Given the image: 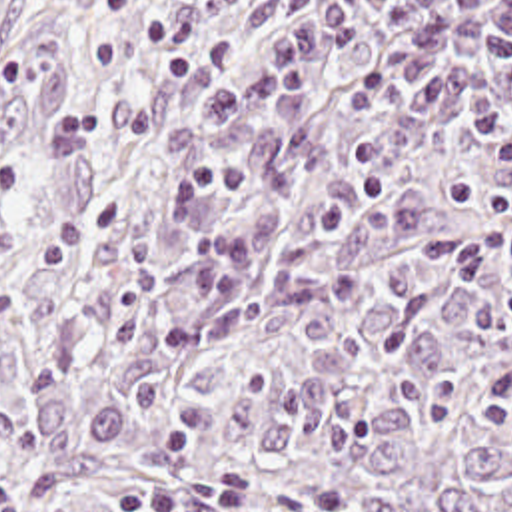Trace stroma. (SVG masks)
I'll use <instances>...</instances> for the list:
<instances>
[{"label": "stroma", "instance_id": "obj_1", "mask_svg": "<svg viewBox=\"0 0 512 512\" xmlns=\"http://www.w3.org/2000/svg\"><path fill=\"white\" fill-rule=\"evenodd\" d=\"M66 0H0V75L16 55L46 33Z\"/></svg>", "mask_w": 512, "mask_h": 512}]
</instances>
